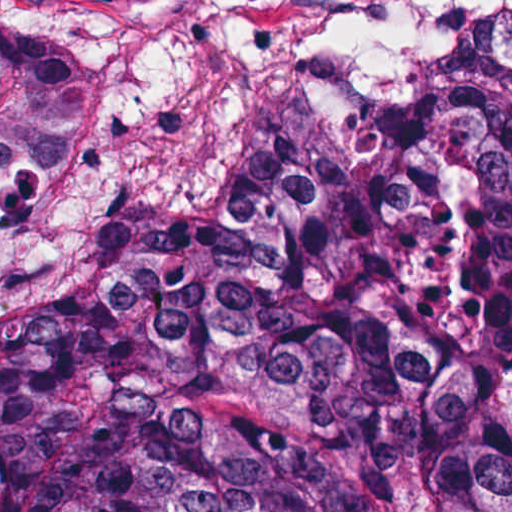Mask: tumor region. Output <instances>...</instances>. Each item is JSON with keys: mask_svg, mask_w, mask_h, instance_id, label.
<instances>
[{"mask_svg": "<svg viewBox=\"0 0 512 512\" xmlns=\"http://www.w3.org/2000/svg\"><path fill=\"white\" fill-rule=\"evenodd\" d=\"M104 74L0 20V169ZM0 512H512V74L388 108L260 43L186 118L125 273L0 319Z\"/></svg>", "mask_w": 512, "mask_h": 512, "instance_id": "e687c5a6", "label": "tumor region"}]
</instances>
